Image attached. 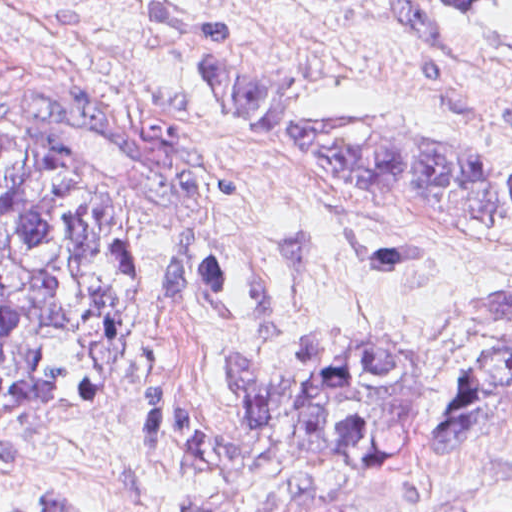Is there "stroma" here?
I'll use <instances>...</instances> for the list:
<instances>
[{
  "label": "stroma",
  "instance_id": "stroma-1",
  "mask_svg": "<svg viewBox=\"0 0 512 512\" xmlns=\"http://www.w3.org/2000/svg\"><path fill=\"white\" fill-rule=\"evenodd\" d=\"M160 0H0V136L121 216L133 300L106 400L0 408V512H512V418L455 446L291 452L285 441L174 476L145 425L163 382L198 424L234 420L236 359L292 384L301 340L393 346L441 414L512 342V225L361 197L288 160L204 84ZM220 13L240 52L316 114H380L512 162L506 43L399 0H162ZM512 19V0H493Z\"/></svg>",
  "mask_w": 512,
  "mask_h": 512
}]
</instances>
